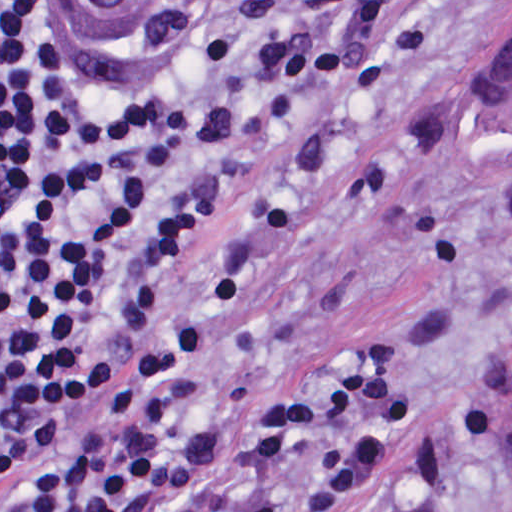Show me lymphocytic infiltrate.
I'll list each match as a JSON object with an SVG mask.
<instances>
[{
  "mask_svg": "<svg viewBox=\"0 0 512 512\" xmlns=\"http://www.w3.org/2000/svg\"><path fill=\"white\" fill-rule=\"evenodd\" d=\"M379 193L191 14L0 0V512H350L413 469L467 325L258 364L286 268Z\"/></svg>",
  "mask_w": 512,
  "mask_h": 512,
  "instance_id": "lymphocytic-infiltrate-1",
  "label": "lymphocytic infiltrate"
}]
</instances>
